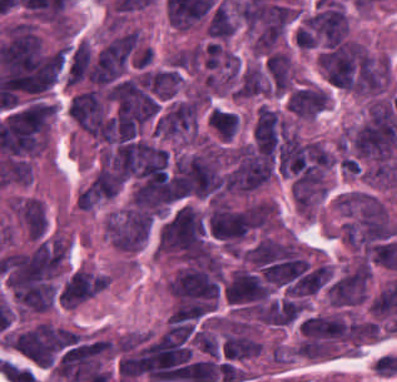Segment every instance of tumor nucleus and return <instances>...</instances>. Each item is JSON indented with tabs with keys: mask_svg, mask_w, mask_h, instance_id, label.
Segmentation results:
<instances>
[{
	"mask_svg": "<svg viewBox=\"0 0 397 382\" xmlns=\"http://www.w3.org/2000/svg\"><path fill=\"white\" fill-rule=\"evenodd\" d=\"M65 252L66 241L46 233L3 253L0 270L16 311H45L60 301Z\"/></svg>",
	"mask_w": 397,
	"mask_h": 382,
	"instance_id": "obj_1",
	"label": "tumor nucleus"
},
{
	"mask_svg": "<svg viewBox=\"0 0 397 382\" xmlns=\"http://www.w3.org/2000/svg\"><path fill=\"white\" fill-rule=\"evenodd\" d=\"M318 70L325 82L342 91L373 95L383 84L382 63L349 37H332L316 49Z\"/></svg>",
	"mask_w": 397,
	"mask_h": 382,
	"instance_id": "obj_2",
	"label": "tumor nucleus"
},
{
	"mask_svg": "<svg viewBox=\"0 0 397 382\" xmlns=\"http://www.w3.org/2000/svg\"><path fill=\"white\" fill-rule=\"evenodd\" d=\"M337 209L346 241L359 246L391 236L397 229L381 201L353 191L338 198Z\"/></svg>",
	"mask_w": 397,
	"mask_h": 382,
	"instance_id": "obj_3",
	"label": "tumor nucleus"
},
{
	"mask_svg": "<svg viewBox=\"0 0 397 382\" xmlns=\"http://www.w3.org/2000/svg\"><path fill=\"white\" fill-rule=\"evenodd\" d=\"M70 329L39 321L6 334L5 345L39 365H50L69 345Z\"/></svg>",
	"mask_w": 397,
	"mask_h": 382,
	"instance_id": "obj_4",
	"label": "tumor nucleus"
},
{
	"mask_svg": "<svg viewBox=\"0 0 397 382\" xmlns=\"http://www.w3.org/2000/svg\"><path fill=\"white\" fill-rule=\"evenodd\" d=\"M108 349L106 340L81 341L60 356L54 376L64 381L81 382L100 368Z\"/></svg>",
	"mask_w": 397,
	"mask_h": 382,
	"instance_id": "obj_5",
	"label": "tumor nucleus"
},
{
	"mask_svg": "<svg viewBox=\"0 0 397 382\" xmlns=\"http://www.w3.org/2000/svg\"><path fill=\"white\" fill-rule=\"evenodd\" d=\"M148 224L149 215L144 210L128 206L108 217L105 237L116 249L134 252L145 242Z\"/></svg>",
	"mask_w": 397,
	"mask_h": 382,
	"instance_id": "obj_6",
	"label": "tumor nucleus"
},
{
	"mask_svg": "<svg viewBox=\"0 0 397 382\" xmlns=\"http://www.w3.org/2000/svg\"><path fill=\"white\" fill-rule=\"evenodd\" d=\"M135 45L134 31H126L106 42L93 61V79L109 82L123 68Z\"/></svg>",
	"mask_w": 397,
	"mask_h": 382,
	"instance_id": "obj_7",
	"label": "tumor nucleus"
},
{
	"mask_svg": "<svg viewBox=\"0 0 397 382\" xmlns=\"http://www.w3.org/2000/svg\"><path fill=\"white\" fill-rule=\"evenodd\" d=\"M368 274L367 264L359 258L329 285L328 300L337 306L362 301Z\"/></svg>",
	"mask_w": 397,
	"mask_h": 382,
	"instance_id": "obj_8",
	"label": "tumor nucleus"
},
{
	"mask_svg": "<svg viewBox=\"0 0 397 382\" xmlns=\"http://www.w3.org/2000/svg\"><path fill=\"white\" fill-rule=\"evenodd\" d=\"M106 275L78 268L59 292L61 306H75L104 290Z\"/></svg>",
	"mask_w": 397,
	"mask_h": 382,
	"instance_id": "obj_9",
	"label": "tumor nucleus"
},
{
	"mask_svg": "<svg viewBox=\"0 0 397 382\" xmlns=\"http://www.w3.org/2000/svg\"><path fill=\"white\" fill-rule=\"evenodd\" d=\"M272 291L258 274L237 268L224 287L225 300L234 302L263 301Z\"/></svg>",
	"mask_w": 397,
	"mask_h": 382,
	"instance_id": "obj_10",
	"label": "tumor nucleus"
},
{
	"mask_svg": "<svg viewBox=\"0 0 397 382\" xmlns=\"http://www.w3.org/2000/svg\"><path fill=\"white\" fill-rule=\"evenodd\" d=\"M283 130V121L271 108L261 105L254 124L252 136L257 148L274 153Z\"/></svg>",
	"mask_w": 397,
	"mask_h": 382,
	"instance_id": "obj_11",
	"label": "tumor nucleus"
},
{
	"mask_svg": "<svg viewBox=\"0 0 397 382\" xmlns=\"http://www.w3.org/2000/svg\"><path fill=\"white\" fill-rule=\"evenodd\" d=\"M273 94H280L290 85V60L283 53L271 52L264 61Z\"/></svg>",
	"mask_w": 397,
	"mask_h": 382,
	"instance_id": "obj_12",
	"label": "tumor nucleus"
},
{
	"mask_svg": "<svg viewBox=\"0 0 397 382\" xmlns=\"http://www.w3.org/2000/svg\"><path fill=\"white\" fill-rule=\"evenodd\" d=\"M261 343L241 332L226 333L222 350L225 358H244L257 355Z\"/></svg>",
	"mask_w": 397,
	"mask_h": 382,
	"instance_id": "obj_13",
	"label": "tumor nucleus"
},
{
	"mask_svg": "<svg viewBox=\"0 0 397 382\" xmlns=\"http://www.w3.org/2000/svg\"><path fill=\"white\" fill-rule=\"evenodd\" d=\"M206 122L218 138H232L239 127V118L232 111L212 106L207 112Z\"/></svg>",
	"mask_w": 397,
	"mask_h": 382,
	"instance_id": "obj_14",
	"label": "tumor nucleus"
},
{
	"mask_svg": "<svg viewBox=\"0 0 397 382\" xmlns=\"http://www.w3.org/2000/svg\"><path fill=\"white\" fill-rule=\"evenodd\" d=\"M268 93L259 68L249 65L241 74L234 90L233 97H247L252 95Z\"/></svg>",
	"mask_w": 397,
	"mask_h": 382,
	"instance_id": "obj_15",
	"label": "tumor nucleus"
},
{
	"mask_svg": "<svg viewBox=\"0 0 397 382\" xmlns=\"http://www.w3.org/2000/svg\"><path fill=\"white\" fill-rule=\"evenodd\" d=\"M234 27V21L229 9L226 3L222 0L213 10L205 27V33L210 37L226 39Z\"/></svg>",
	"mask_w": 397,
	"mask_h": 382,
	"instance_id": "obj_16",
	"label": "tumor nucleus"
}]
</instances>
